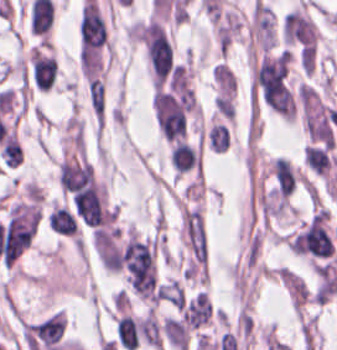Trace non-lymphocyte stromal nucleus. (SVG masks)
Segmentation results:
<instances>
[{"label": "non-lymphocyte stromal nucleus", "mask_w": 337, "mask_h": 350, "mask_svg": "<svg viewBox=\"0 0 337 350\" xmlns=\"http://www.w3.org/2000/svg\"><path fill=\"white\" fill-rule=\"evenodd\" d=\"M138 332L142 341L155 350H161V335L158 322L149 308L138 320Z\"/></svg>", "instance_id": "non-lymphocyte-stromal-nucleus-1"}]
</instances>
